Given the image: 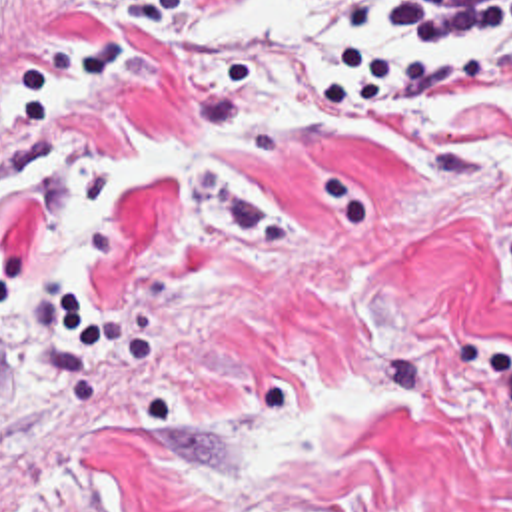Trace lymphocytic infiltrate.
Masks as SVG:
<instances>
[{
  "mask_svg": "<svg viewBox=\"0 0 512 512\" xmlns=\"http://www.w3.org/2000/svg\"><path fill=\"white\" fill-rule=\"evenodd\" d=\"M202 0H134L132 23L180 19ZM331 19L328 106H435L491 82L479 62H409L375 38L477 42L512 34V0H302Z\"/></svg>",
  "mask_w": 512,
  "mask_h": 512,
  "instance_id": "1",
  "label": "lymphocytic infiltrate"
}]
</instances>
